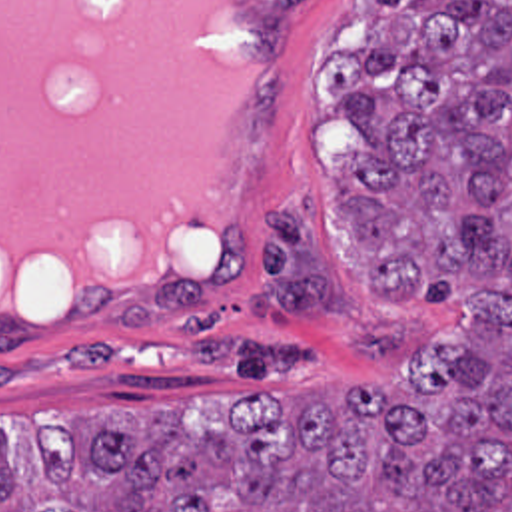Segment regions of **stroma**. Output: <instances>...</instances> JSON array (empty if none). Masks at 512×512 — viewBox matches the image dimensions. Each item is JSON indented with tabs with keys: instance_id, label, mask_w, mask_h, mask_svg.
Here are the masks:
<instances>
[{
	"instance_id": "stroma-1",
	"label": "stroma",
	"mask_w": 512,
	"mask_h": 512,
	"mask_svg": "<svg viewBox=\"0 0 512 512\" xmlns=\"http://www.w3.org/2000/svg\"><path fill=\"white\" fill-rule=\"evenodd\" d=\"M235 2L257 30V88L223 236L203 268L171 284L93 288L51 324L0 314V435L21 475L41 461L33 435L79 417L215 429L249 393L303 409L339 401L353 383L394 389L456 322L450 310L380 304L355 234L333 226L359 136L327 102L321 74L368 48L370 0ZM301 200L345 312L263 318L249 294L261 282L265 214Z\"/></svg>"
}]
</instances>
